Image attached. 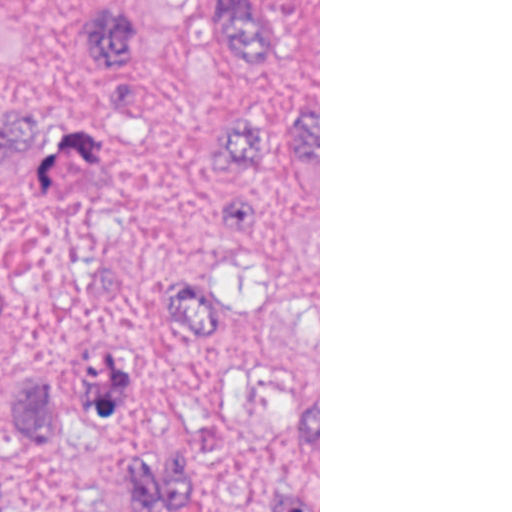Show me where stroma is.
Instances as JSON below:
<instances>
[{"label": "stroma", "mask_w": 512, "mask_h": 512, "mask_svg": "<svg viewBox=\"0 0 512 512\" xmlns=\"http://www.w3.org/2000/svg\"><path fill=\"white\" fill-rule=\"evenodd\" d=\"M281 1L285 42L251 60L215 42L213 0H0V476L38 457L29 386L83 393L87 376H122L197 452L234 419L232 366L172 319L186 283L238 277L221 211L255 173L215 136H136L51 195L25 174L37 143L224 100L277 114L318 87L320 512V0Z\"/></svg>", "instance_id": "35a3bbf8"}]
</instances>
